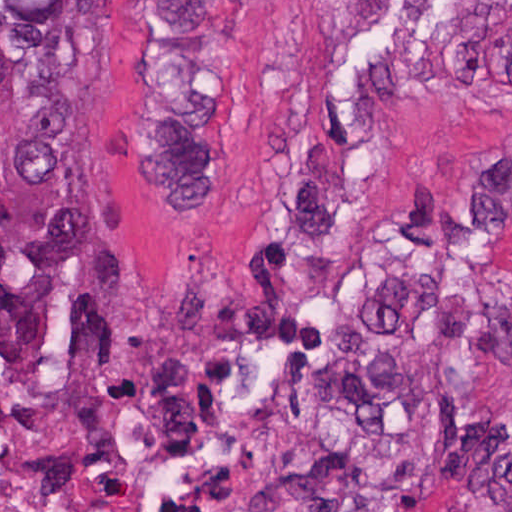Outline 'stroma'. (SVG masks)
<instances>
[{
	"mask_svg": "<svg viewBox=\"0 0 512 512\" xmlns=\"http://www.w3.org/2000/svg\"><path fill=\"white\" fill-rule=\"evenodd\" d=\"M156 0H78L133 354L0 377L66 512H512V0H227L220 181L153 183Z\"/></svg>",
	"mask_w": 512,
	"mask_h": 512,
	"instance_id": "stroma-1",
	"label": "stroma"
}]
</instances>
